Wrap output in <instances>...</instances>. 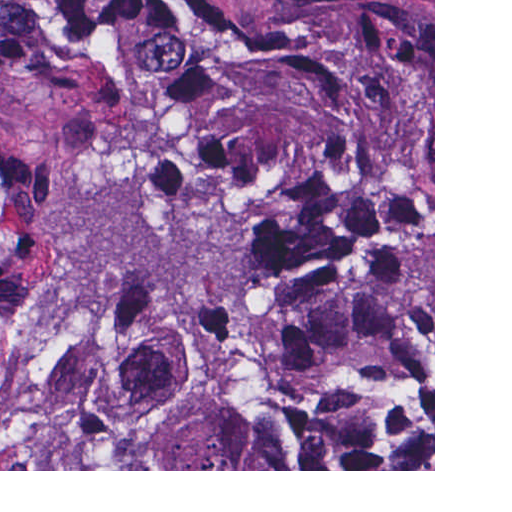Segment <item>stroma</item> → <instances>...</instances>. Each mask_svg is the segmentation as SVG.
Here are the masks:
<instances>
[{
  "label": "stroma",
  "mask_w": 512,
  "mask_h": 512,
  "mask_svg": "<svg viewBox=\"0 0 512 512\" xmlns=\"http://www.w3.org/2000/svg\"><path fill=\"white\" fill-rule=\"evenodd\" d=\"M0 199V230L9 223ZM35 322L0 324V471H435V0H433V469H32Z\"/></svg>",
  "instance_id": "obj_1"
}]
</instances>
